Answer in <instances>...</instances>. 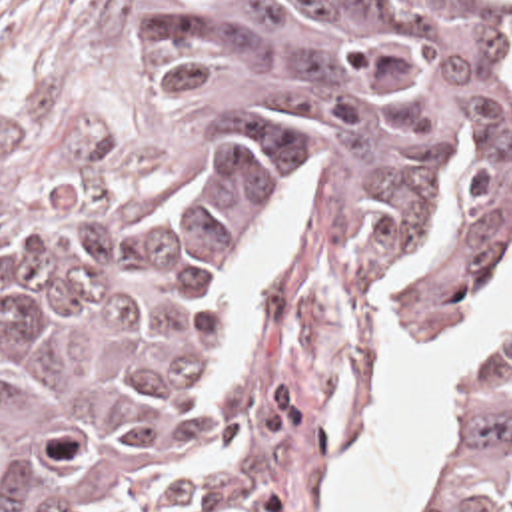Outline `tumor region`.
I'll return each instance as SVG.
<instances>
[{"label":"tumor region","mask_w":512,"mask_h":512,"mask_svg":"<svg viewBox=\"0 0 512 512\" xmlns=\"http://www.w3.org/2000/svg\"><path fill=\"white\" fill-rule=\"evenodd\" d=\"M172 162L0 188V512H323L395 346L512 260L509 0H142ZM431 512H512V338Z\"/></svg>","instance_id":"obj_1"}]
</instances>
